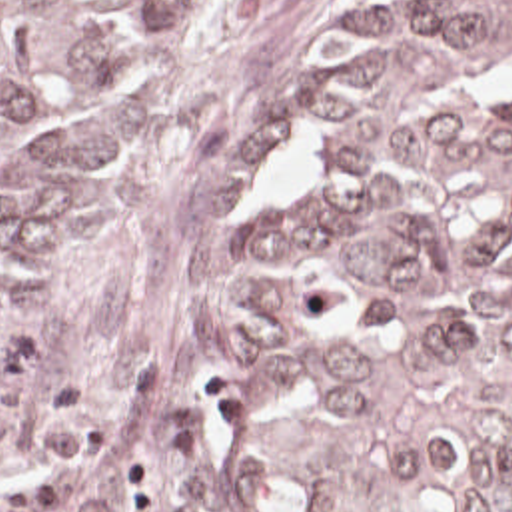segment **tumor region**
<instances>
[{
  "label": "tumor region",
  "mask_w": 512,
  "mask_h": 512,
  "mask_svg": "<svg viewBox=\"0 0 512 512\" xmlns=\"http://www.w3.org/2000/svg\"><path fill=\"white\" fill-rule=\"evenodd\" d=\"M251 0H0V294ZM223 358L273 512H512V0H355Z\"/></svg>",
  "instance_id": "tumor-region-1"
}]
</instances>
